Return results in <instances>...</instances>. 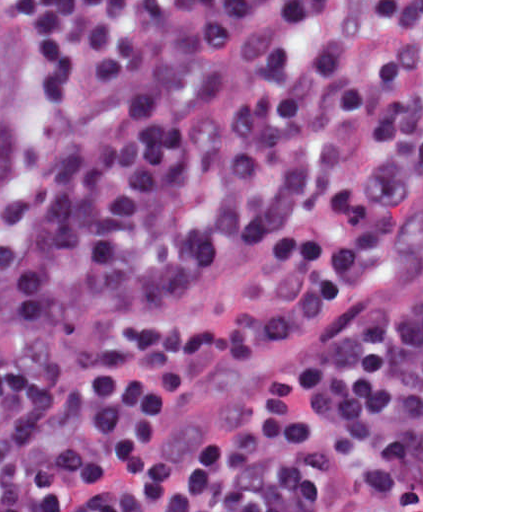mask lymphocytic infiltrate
Here are the masks:
<instances>
[{"mask_svg": "<svg viewBox=\"0 0 512 512\" xmlns=\"http://www.w3.org/2000/svg\"><path fill=\"white\" fill-rule=\"evenodd\" d=\"M368 0H14L36 147L0 246V512H294V367L174 467L161 413L202 357L294 341V133ZM257 252L280 305L164 317Z\"/></svg>", "mask_w": 512, "mask_h": 512, "instance_id": "1", "label": "lymphocytic infiltrate"}]
</instances>
